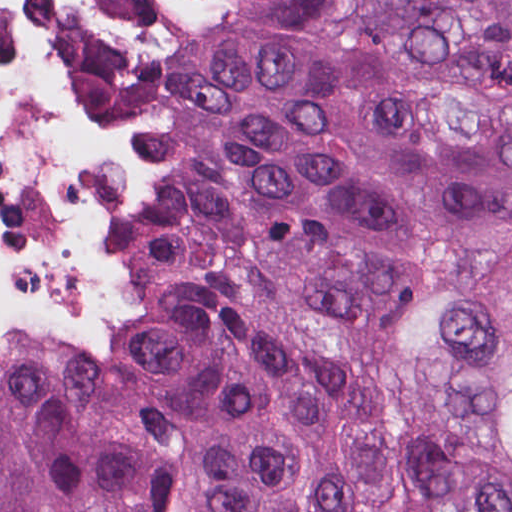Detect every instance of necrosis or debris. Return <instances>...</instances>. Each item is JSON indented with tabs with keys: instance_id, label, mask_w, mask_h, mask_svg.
<instances>
[{
	"instance_id": "necrosis-or-debris-1",
	"label": "necrosis or debris",
	"mask_w": 512,
	"mask_h": 512,
	"mask_svg": "<svg viewBox=\"0 0 512 512\" xmlns=\"http://www.w3.org/2000/svg\"><path fill=\"white\" fill-rule=\"evenodd\" d=\"M160 251V207L88 54V0H0V344L86 350Z\"/></svg>"
}]
</instances>
